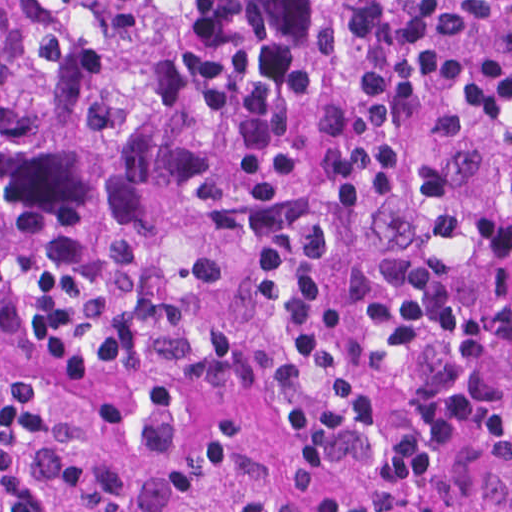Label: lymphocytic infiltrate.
Segmentation results:
<instances>
[{
    "label": "lymphocytic infiltrate",
    "mask_w": 512,
    "mask_h": 512,
    "mask_svg": "<svg viewBox=\"0 0 512 512\" xmlns=\"http://www.w3.org/2000/svg\"><path fill=\"white\" fill-rule=\"evenodd\" d=\"M221 512H273L267 450L313 512H418L458 463L512 466V180L423 209L217 428Z\"/></svg>",
    "instance_id": "lymphocytic-infiltrate-1"
}]
</instances>
